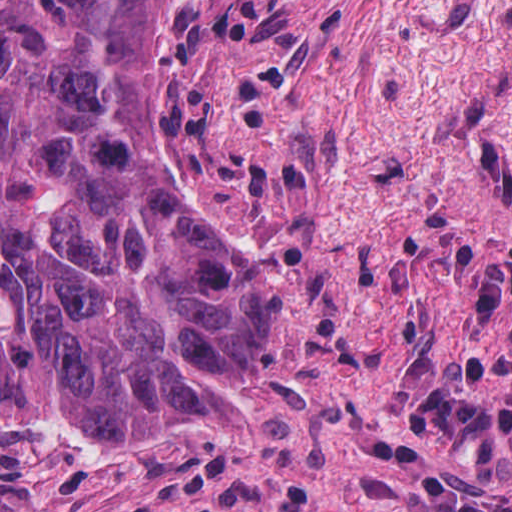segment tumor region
Here are the masks:
<instances>
[{
    "instance_id": "e687c5a6",
    "label": "tumor region",
    "mask_w": 512,
    "mask_h": 512,
    "mask_svg": "<svg viewBox=\"0 0 512 512\" xmlns=\"http://www.w3.org/2000/svg\"><path fill=\"white\" fill-rule=\"evenodd\" d=\"M165 2L1 1V423L135 447L263 425L241 377L283 292L156 151Z\"/></svg>"
}]
</instances>
